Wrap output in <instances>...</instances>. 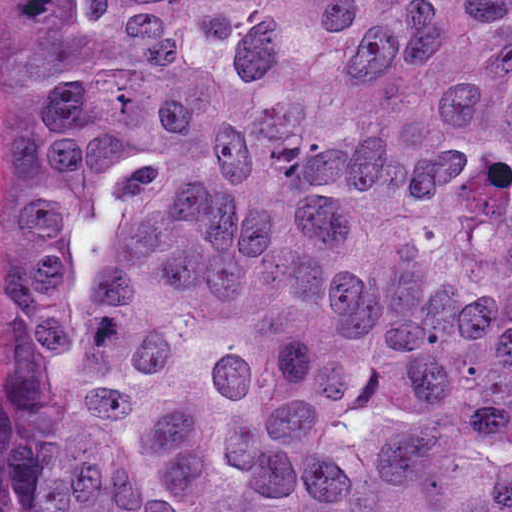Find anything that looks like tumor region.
I'll use <instances>...</instances> for the list:
<instances>
[{
	"label": "tumor region",
	"mask_w": 512,
	"mask_h": 512,
	"mask_svg": "<svg viewBox=\"0 0 512 512\" xmlns=\"http://www.w3.org/2000/svg\"><path fill=\"white\" fill-rule=\"evenodd\" d=\"M0 512H512V0H21Z\"/></svg>",
	"instance_id": "obj_1"
}]
</instances>
